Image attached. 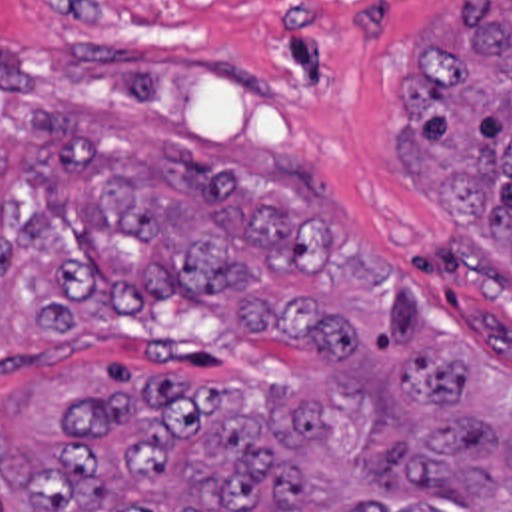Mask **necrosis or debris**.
Masks as SVG:
<instances>
[{"label": "necrosis or debris", "instance_id": "necrosis-or-debris-1", "mask_svg": "<svg viewBox=\"0 0 512 512\" xmlns=\"http://www.w3.org/2000/svg\"><path fill=\"white\" fill-rule=\"evenodd\" d=\"M42 11H125L183 13L189 9H225L251 0H14ZM347 1V0H321Z\"/></svg>", "mask_w": 512, "mask_h": 512}]
</instances>
